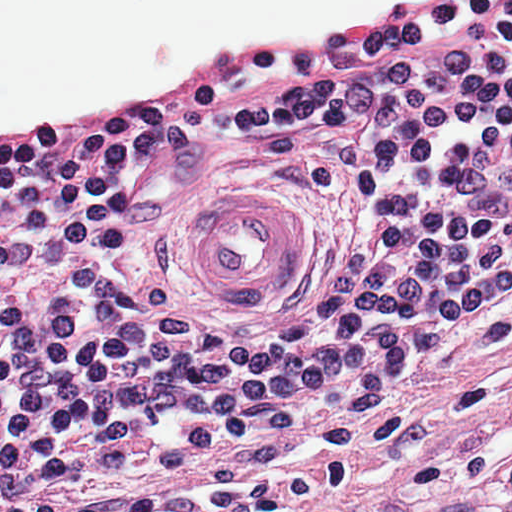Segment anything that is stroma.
Masks as SVG:
<instances>
[{
    "label": "stroma",
    "instance_id": "obj_1",
    "mask_svg": "<svg viewBox=\"0 0 512 512\" xmlns=\"http://www.w3.org/2000/svg\"><path fill=\"white\" fill-rule=\"evenodd\" d=\"M406 0H374L309 26L242 35L207 49L187 72L105 101L0 121V133L69 130L131 107L195 94V141L143 147L133 175L163 231L164 287L181 318L244 338L296 321L386 221V205L351 185L295 175L245 122L282 95L285 77L258 55L372 27ZM254 182L299 225V268L253 306L214 296L197 270V198ZM170 512H512V311L434 352L387 389L351 430L265 462L228 491Z\"/></svg>",
    "mask_w": 512,
    "mask_h": 512
}]
</instances>
